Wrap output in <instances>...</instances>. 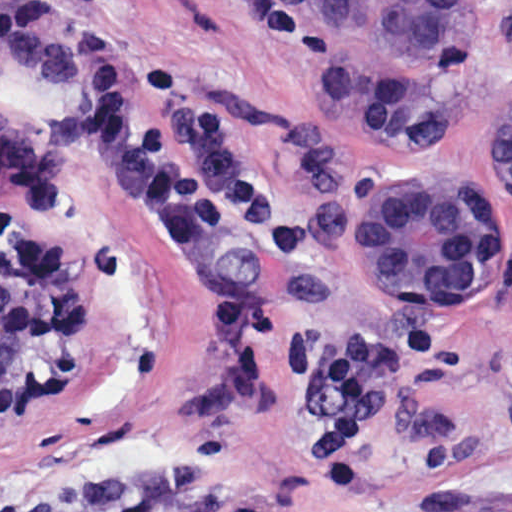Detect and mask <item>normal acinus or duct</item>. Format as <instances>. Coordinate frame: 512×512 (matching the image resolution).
<instances>
[{"label": "normal acinus or duct", "instance_id": "normal-acinus-or-duct-1", "mask_svg": "<svg viewBox=\"0 0 512 512\" xmlns=\"http://www.w3.org/2000/svg\"><path fill=\"white\" fill-rule=\"evenodd\" d=\"M328 96L351 131L383 140L435 136L469 100L488 0H288ZM512 190V109L490 147ZM439 178L396 177L357 201L353 246L389 307L476 311L498 283L495 212ZM60 283L37 244L0 262V394L50 353Z\"/></svg>", "mask_w": 512, "mask_h": 512}]
</instances>
